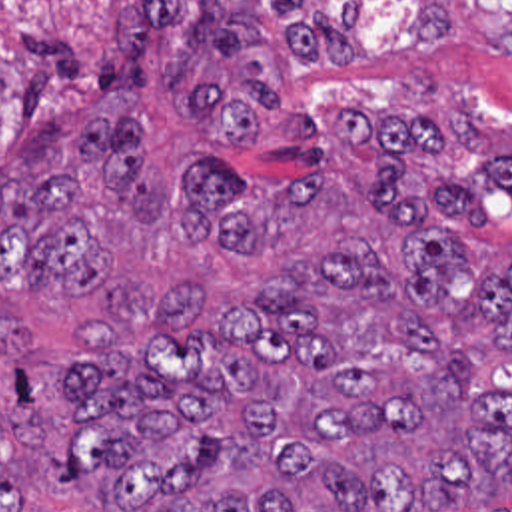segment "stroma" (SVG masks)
<instances>
[{
	"instance_id": "obj_1",
	"label": "stroma",
	"mask_w": 512,
	"mask_h": 512,
	"mask_svg": "<svg viewBox=\"0 0 512 512\" xmlns=\"http://www.w3.org/2000/svg\"><path fill=\"white\" fill-rule=\"evenodd\" d=\"M143 0H0V172L39 180L75 172L93 192L97 234V290L75 298L47 282L13 298L9 316L27 324L29 344L0 372V406L13 400L19 374H35L69 360L85 330L107 316L111 292L145 286L163 296L187 282L209 286L203 326L229 302L267 288L285 262L313 260L339 236L368 238L398 258L400 224L376 214L366 192V152L343 132L345 104H361L386 118L420 116L438 126L442 156L412 154L408 176L460 178L500 166L512 154V54L496 44L492 22L466 0H448L450 40L418 50L412 34L416 0H219L229 18L251 20L263 34L241 54H211L195 86L233 96L245 62L257 64L279 90V112L261 120L255 148H221L215 132L189 114V90H167L165 68L181 34L189 32L201 0H169L173 26L155 32L147 48L145 92H107L103 58L123 70L121 12ZM355 6V58L295 60L285 30L309 16L339 18ZM512 6V0H482ZM107 124L131 116L145 136L143 162L165 174L163 224H133L121 188L101 168L79 166L75 136L97 118ZM221 160L231 170L299 182L317 178V192L295 210L277 246H179L173 212L183 196L185 162ZM219 164V162H215ZM223 166V164H219ZM488 230L472 234L486 268L502 272L512 260V192H498L486 212ZM23 512H99L109 495L47 489L39 447L21 461ZM434 512H512V485L498 497Z\"/></svg>"
}]
</instances>
